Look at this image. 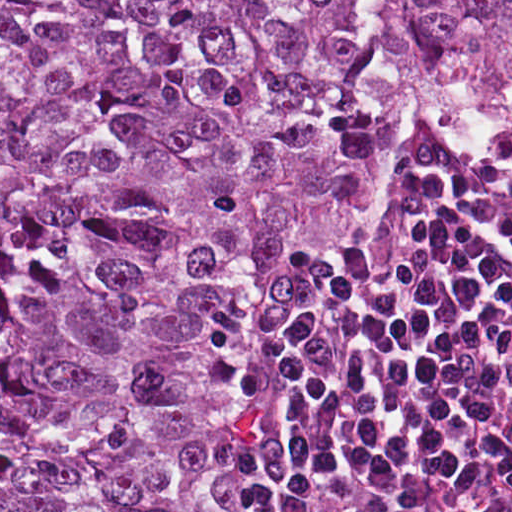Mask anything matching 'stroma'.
<instances>
[{
    "instance_id": "35a3bbf8",
    "label": "stroma",
    "mask_w": 512,
    "mask_h": 512,
    "mask_svg": "<svg viewBox=\"0 0 512 512\" xmlns=\"http://www.w3.org/2000/svg\"><path fill=\"white\" fill-rule=\"evenodd\" d=\"M422 145L435 153L456 155L442 152L424 124L410 128L403 143L397 174L388 190L383 218L374 234L364 241H335L323 233L295 235L281 242L263 267L253 316V396L231 436L229 447V478L237 512H252L237 496V475L240 461L251 451L258 427V408L263 398L265 384V343L273 277L288 260L304 252H369L387 225L394 199L407 173L410 155ZM506 147H510L512 171V132H504L491 150Z\"/></svg>"
}]
</instances>
